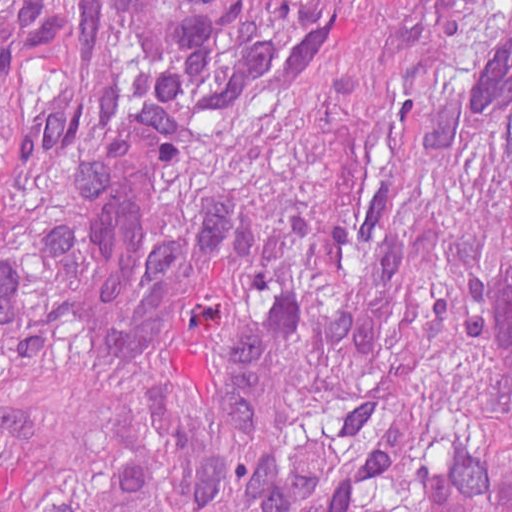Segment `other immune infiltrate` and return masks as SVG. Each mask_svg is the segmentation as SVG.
Returning <instances> with one entry per match:
<instances>
[{"instance_id":"1","label":"other immune infiltrate","mask_w":512,"mask_h":512,"mask_svg":"<svg viewBox=\"0 0 512 512\" xmlns=\"http://www.w3.org/2000/svg\"><path fill=\"white\" fill-rule=\"evenodd\" d=\"M12 184L0 152V326L14 325L18 313ZM69 223L94 331L107 348L136 342L176 287L214 267L247 268L267 236V219L244 203L229 201L193 217L150 200L140 163L124 144L86 166L69 203Z\"/></svg>"}]
</instances>
